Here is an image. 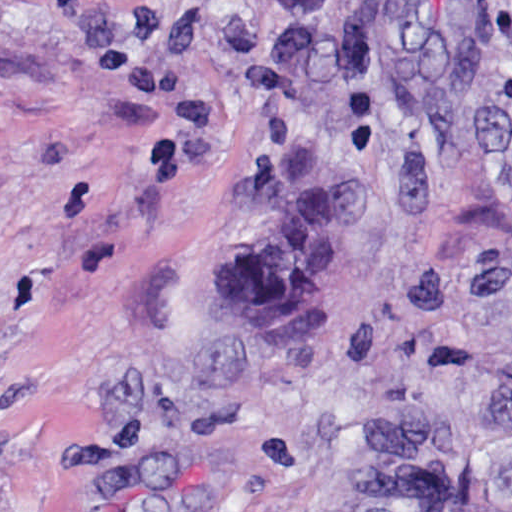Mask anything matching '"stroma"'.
Listing matches in <instances>:
<instances>
[{
	"label": "stroma",
	"instance_id": "35a3bbf8",
	"mask_svg": "<svg viewBox=\"0 0 512 512\" xmlns=\"http://www.w3.org/2000/svg\"><path fill=\"white\" fill-rule=\"evenodd\" d=\"M0 512H512V0H0Z\"/></svg>",
	"mask_w": 512,
	"mask_h": 512
}]
</instances>
